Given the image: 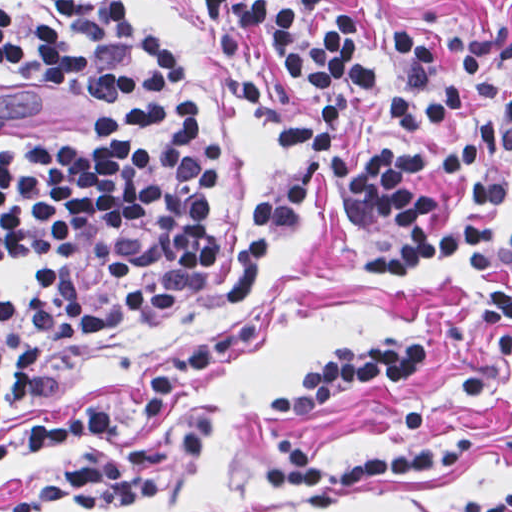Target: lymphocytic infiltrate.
I'll list each match as a JSON object with an SVG mask.
<instances>
[{
  "mask_svg": "<svg viewBox=\"0 0 512 512\" xmlns=\"http://www.w3.org/2000/svg\"><path fill=\"white\" fill-rule=\"evenodd\" d=\"M209 16L224 71L247 35L260 31L299 85L361 97L394 95L399 130L434 125L450 150L437 170L466 174L463 209L455 192L396 143L373 162L340 147L343 118L324 104L311 119L273 109L254 69L233 86L283 143L308 148L333 169L342 210L359 222L390 219L403 245L357 260L387 275L451 259L465 246L469 270L488 278L481 311L512 372V222L499 235L497 210L508 179L482 166V149L512 145V30H462L450 65L414 31L389 28L377 0L388 61L403 92L383 93L358 16L326 0H197ZM1 64L60 94L98 102L94 142L44 136L1 141V386L15 426L0 433V468L49 451L8 512H118L146 503L163 484V423L184 398L240 360L260 331L249 308L272 253L309 204L302 179L263 199L248 216L220 329L160 366L139 393L128 444L71 457L69 439L106 425L111 405L60 418H29L57 370L103 345L164 323L189 303L224 241L211 225L220 167L200 104L174 51L140 25L124 0H1ZM422 340L396 334L360 349H334L303 379L299 394L270 411L310 414L367 384L394 385L425 371ZM412 454L325 466L293 436L271 442L278 463L266 482L301 495L308 509L337 505L346 491L381 477L454 471L476 439L431 434L423 409L404 416ZM454 512H512V482Z\"/></svg>",
  "mask_w": 512,
  "mask_h": 512,
  "instance_id": "lymphocytic-infiltrate-1",
  "label": "lymphocytic infiltrate"
}]
</instances>
